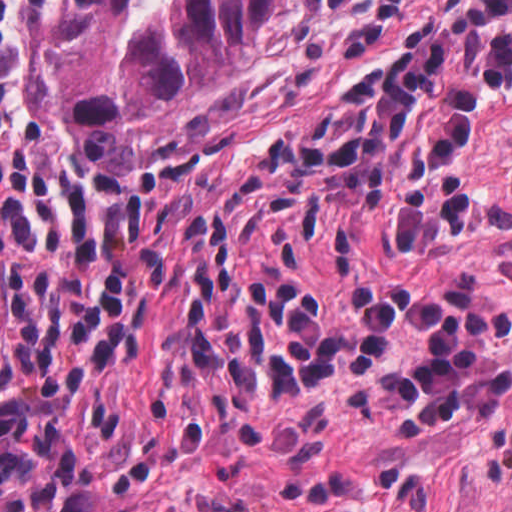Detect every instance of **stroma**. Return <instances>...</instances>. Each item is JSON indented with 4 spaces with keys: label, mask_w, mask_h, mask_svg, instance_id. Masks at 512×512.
<instances>
[{
    "label": "stroma",
    "mask_w": 512,
    "mask_h": 512,
    "mask_svg": "<svg viewBox=\"0 0 512 512\" xmlns=\"http://www.w3.org/2000/svg\"><path fill=\"white\" fill-rule=\"evenodd\" d=\"M407 0H279L262 44L225 84L199 101V120L252 91ZM79 0H56L23 26V96L19 140L23 158L81 189L107 174L71 146L42 114V51L49 36L77 23ZM162 142V141H161ZM160 142H141V153Z\"/></svg>",
    "instance_id": "35a3bbf8"
}]
</instances>
